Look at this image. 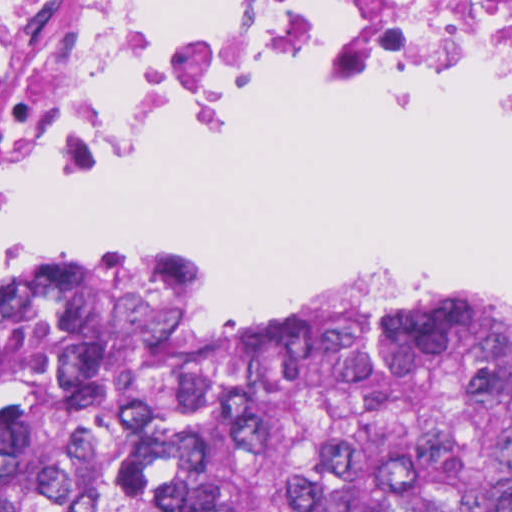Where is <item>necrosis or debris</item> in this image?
<instances>
[{"label":"necrosis or debris","mask_w":512,"mask_h":512,"mask_svg":"<svg viewBox=\"0 0 512 512\" xmlns=\"http://www.w3.org/2000/svg\"><path fill=\"white\" fill-rule=\"evenodd\" d=\"M482 79L512 0H0V207L216 95Z\"/></svg>","instance_id":"4bbe7bcc"}]
</instances>
